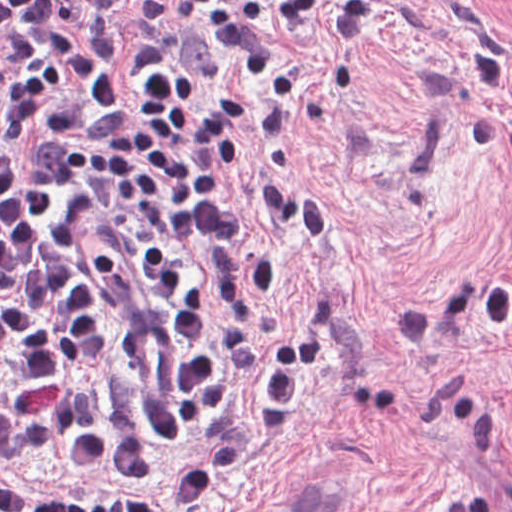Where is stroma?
Returning <instances> with one entry per match:
<instances>
[{
	"mask_svg": "<svg viewBox=\"0 0 512 512\" xmlns=\"http://www.w3.org/2000/svg\"><path fill=\"white\" fill-rule=\"evenodd\" d=\"M148 0H125L112 63L116 98ZM268 26L304 55L300 110L245 81L305 124L291 143L250 140L319 191L334 215L321 250L288 227L257 178H235L276 263L259 301L266 343L230 398L158 434L169 448L235 425L271 379L308 310L333 332L299 382L288 425L213 480L200 509L158 482L93 476L59 449L19 462L22 481L78 496L134 495L157 512H289L345 496L359 512H512V7L499 0H380L350 52L306 22ZM0 365V380L7 379Z\"/></svg>",
	"mask_w": 512,
	"mask_h": 512,
	"instance_id": "1",
	"label": "stroma"
}]
</instances>
